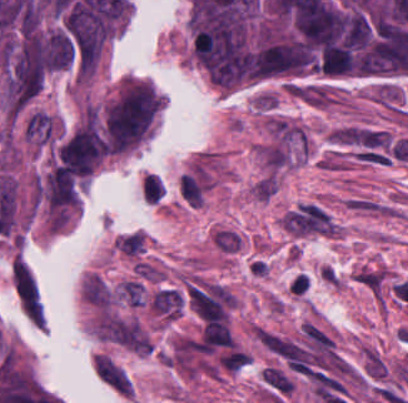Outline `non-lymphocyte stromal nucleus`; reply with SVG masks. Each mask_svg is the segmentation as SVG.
Returning a JSON list of instances; mask_svg holds the SVG:
<instances>
[{
	"label": "non-lymphocyte stromal nucleus",
	"instance_id": "non-lymphocyte-stromal-nucleus-1",
	"mask_svg": "<svg viewBox=\"0 0 408 403\" xmlns=\"http://www.w3.org/2000/svg\"><path fill=\"white\" fill-rule=\"evenodd\" d=\"M210 240L218 252L234 254L238 252L243 239L238 230L218 225L212 230Z\"/></svg>",
	"mask_w": 408,
	"mask_h": 403
}]
</instances>
